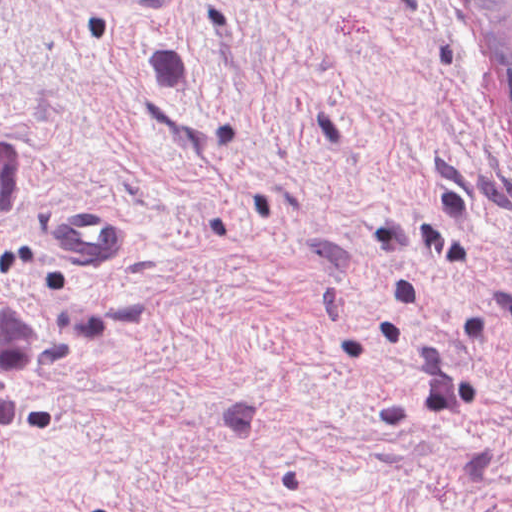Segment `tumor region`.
<instances>
[{
	"label": "tumor region",
	"instance_id": "1",
	"mask_svg": "<svg viewBox=\"0 0 512 512\" xmlns=\"http://www.w3.org/2000/svg\"><path fill=\"white\" fill-rule=\"evenodd\" d=\"M512 106V0H464ZM29 153L0 135V214L25 194ZM111 312L89 294H0V425L25 419L49 367L63 354L99 355Z\"/></svg>",
	"mask_w": 512,
	"mask_h": 512
}]
</instances>
